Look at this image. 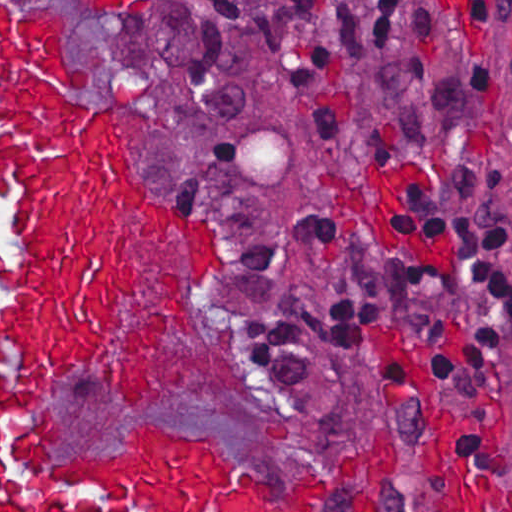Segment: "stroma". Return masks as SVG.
Segmentation results:
<instances>
[{
	"mask_svg": "<svg viewBox=\"0 0 512 512\" xmlns=\"http://www.w3.org/2000/svg\"><path fill=\"white\" fill-rule=\"evenodd\" d=\"M195 1L97 7L91 0H0V512L1 267L17 261L11 232L18 213V190L1 191V8L65 11L61 50L90 71V82L75 95L87 107L112 112L122 160L141 189L218 244L215 264L203 274L179 249L175 233L154 237L139 219L142 299L149 305L177 272L189 273L200 288L204 340L172 323L156 393L140 407H129L98 376L67 374L40 411L49 409L67 427L52 451L58 458L110 453L135 425L172 426L211 436L235 465V478L206 512H219L225 496L274 512L278 503L307 498L330 471L319 512H442L427 422L375 339V327L384 325L435 385L463 466L511 485L512 345L496 369L468 388L460 415L437 383V363L474 339L477 319L465 305L425 339L404 331L390 301L402 252L390 217L401 188L434 178L440 165L436 147H410L393 111L395 78L415 69L413 21L423 11L439 21L446 63L483 60L500 75V96L473 150L507 168L498 210L512 220V26L493 24L459 52L451 1L409 0L394 42L351 75L345 130L317 142L264 47L258 1L245 13L244 98L222 120L192 119L178 94L177 68ZM320 204L315 242L338 258L303 253L290 233L297 215ZM230 240L268 242L279 264L237 282ZM364 286L360 336L367 362L336 348L318 324V313L332 301ZM237 294L302 323L313 381L289 409L254 356Z\"/></svg>",
	"mask_w": 512,
	"mask_h": 512,
	"instance_id": "35a3bbf8",
	"label": "stroma"
}]
</instances>
